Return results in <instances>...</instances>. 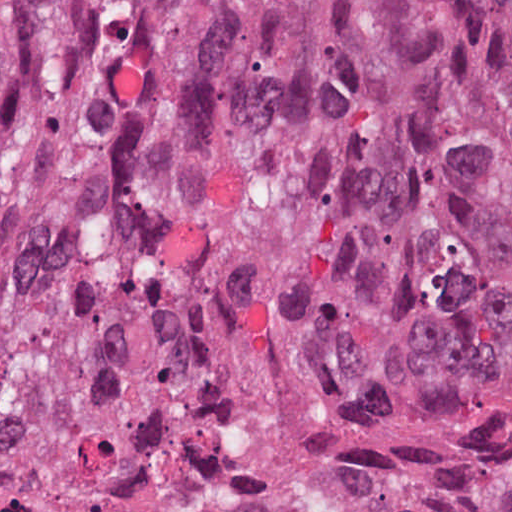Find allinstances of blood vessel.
I'll use <instances>...</instances> for the list:
<instances>
[{
    "instance_id": "obj_1",
    "label": "blood vessel",
    "mask_w": 512,
    "mask_h": 512,
    "mask_svg": "<svg viewBox=\"0 0 512 512\" xmlns=\"http://www.w3.org/2000/svg\"><path fill=\"white\" fill-rule=\"evenodd\" d=\"M28 0H0V48L9 38Z\"/></svg>"
}]
</instances>
